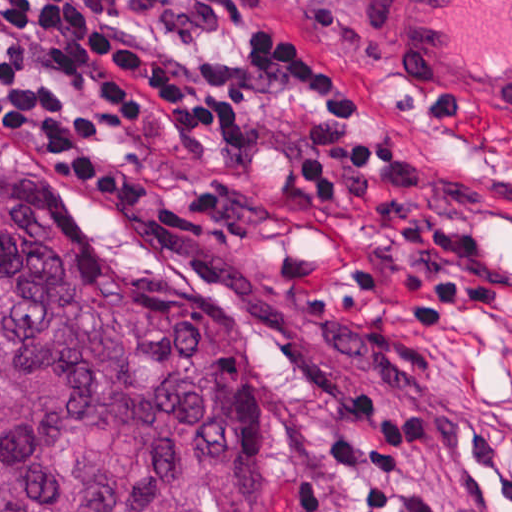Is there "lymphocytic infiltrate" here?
Returning a JSON list of instances; mask_svg holds the SVG:
<instances>
[{"label": "lymphocytic infiltrate", "mask_w": 512, "mask_h": 512, "mask_svg": "<svg viewBox=\"0 0 512 512\" xmlns=\"http://www.w3.org/2000/svg\"><path fill=\"white\" fill-rule=\"evenodd\" d=\"M248 57L258 76L322 104L299 155L313 197H341L347 177L399 154L397 135L351 138L361 110L353 87L300 42L257 33ZM0 115L44 163L113 199H148L178 153L235 148L248 136L234 95L125 38L94 0H0ZM330 398L358 435L337 441L335 453L362 465L357 488L368 512H445L402 469V458L434 435L430 402L393 412L374 385H337Z\"/></svg>", "instance_id": "obj_1"}]
</instances>
